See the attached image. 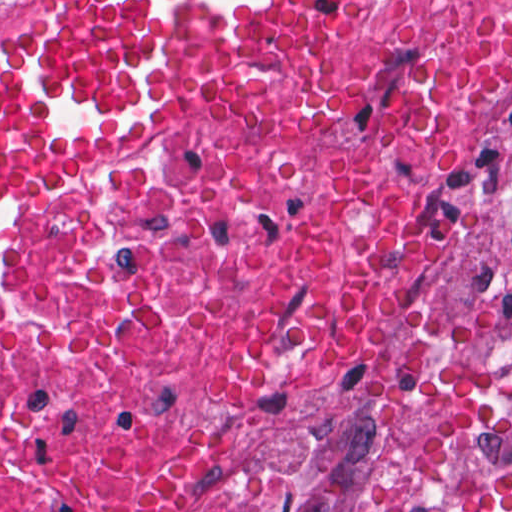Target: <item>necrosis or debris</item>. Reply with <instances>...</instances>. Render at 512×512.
I'll return each mask as SVG.
<instances>
[{"mask_svg": "<svg viewBox=\"0 0 512 512\" xmlns=\"http://www.w3.org/2000/svg\"><path fill=\"white\" fill-rule=\"evenodd\" d=\"M511 67L512 0H394L236 129L0 188V512H512Z\"/></svg>", "mask_w": 512, "mask_h": 512, "instance_id": "1", "label": "necrosis or debris"}]
</instances>
